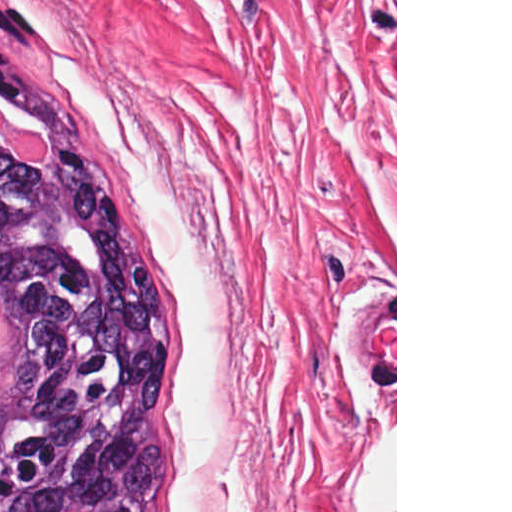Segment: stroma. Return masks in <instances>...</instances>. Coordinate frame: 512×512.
<instances>
[{
    "instance_id": "stroma-1",
    "label": "stroma",
    "mask_w": 512,
    "mask_h": 512,
    "mask_svg": "<svg viewBox=\"0 0 512 512\" xmlns=\"http://www.w3.org/2000/svg\"><path fill=\"white\" fill-rule=\"evenodd\" d=\"M27 1L58 88L84 122L61 56L143 125L214 260L229 375L210 512H279L332 0ZM90 134L173 308L162 413L175 512L180 302L152 227Z\"/></svg>"
}]
</instances>
